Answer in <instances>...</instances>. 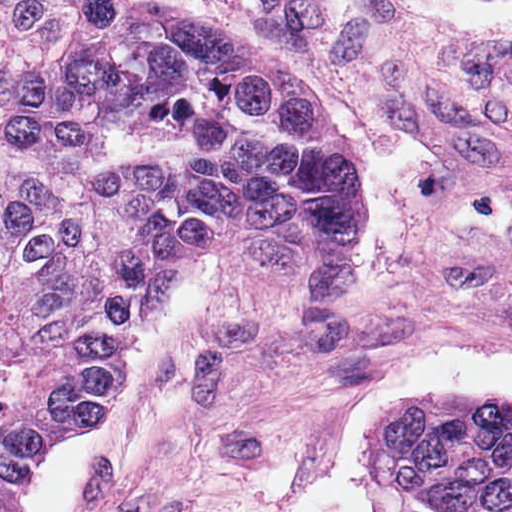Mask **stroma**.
I'll return each instance as SVG.
<instances>
[{
    "instance_id": "1",
    "label": "stroma",
    "mask_w": 512,
    "mask_h": 512,
    "mask_svg": "<svg viewBox=\"0 0 512 512\" xmlns=\"http://www.w3.org/2000/svg\"><path fill=\"white\" fill-rule=\"evenodd\" d=\"M130 2L318 83L361 246L324 291L249 251L189 263L108 413L51 445L81 512H281L373 384L436 355L512 361V29L370 0Z\"/></svg>"
}]
</instances>
